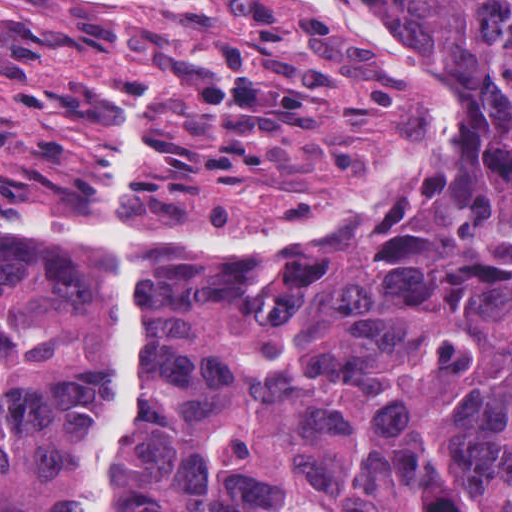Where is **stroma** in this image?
<instances>
[{"instance_id":"obj_1","label":"stroma","mask_w":512,"mask_h":512,"mask_svg":"<svg viewBox=\"0 0 512 512\" xmlns=\"http://www.w3.org/2000/svg\"><path fill=\"white\" fill-rule=\"evenodd\" d=\"M458 124L363 0H0V245L288 254L426 212Z\"/></svg>"}]
</instances>
